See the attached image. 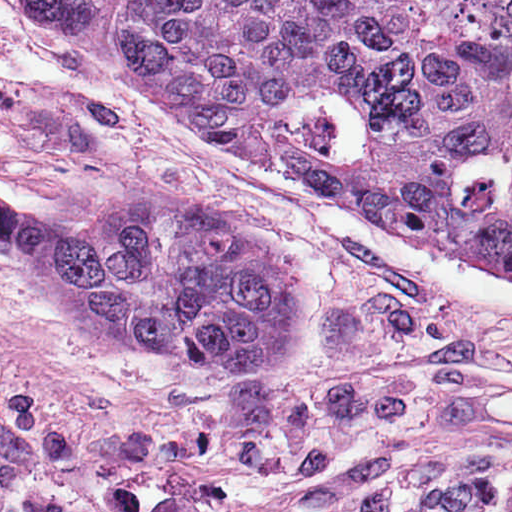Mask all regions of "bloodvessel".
Instances as JSON below:
<instances>
[{
    "label": "blood vessel",
    "mask_w": 512,
    "mask_h": 512,
    "mask_svg": "<svg viewBox=\"0 0 512 512\" xmlns=\"http://www.w3.org/2000/svg\"><path fill=\"white\" fill-rule=\"evenodd\" d=\"M29 455L27 414L0 386V512H6L4 484Z\"/></svg>",
    "instance_id": "8fb6f2fc"
}]
</instances>
